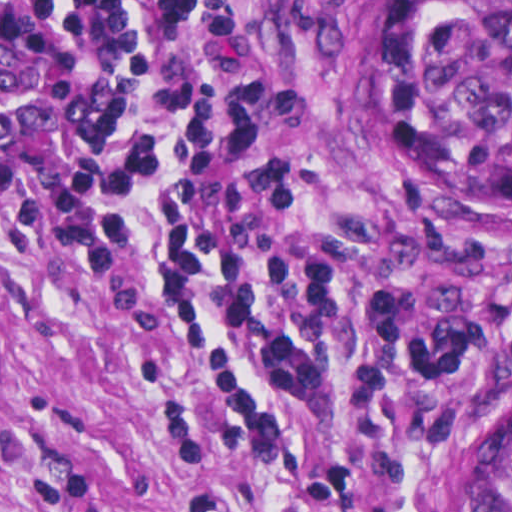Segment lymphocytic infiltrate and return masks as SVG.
<instances>
[{"label":"lymphocytic infiltrate","instance_id":"obj_1","mask_svg":"<svg viewBox=\"0 0 512 512\" xmlns=\"http://www.w3.org/2000/svg\"><path fill=\"white\" fill-rule=\"evenodd\" d=\"M0 193L218 489L387 509L420 434L512 382V262L354 239L306 164L298 44L258 0H0Z\"/></svg>","mask_w":512,"mask_h":512}]
</instances>
